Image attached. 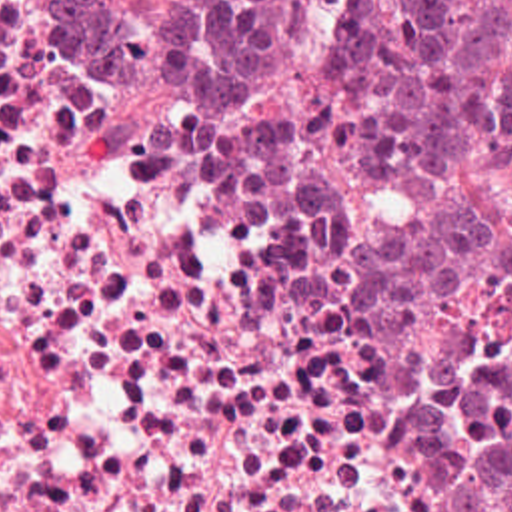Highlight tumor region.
<instances>
[{
	"mask_svg": "<svg viewBox=\"0 0 512 512\" xmlns=\"http://www.w3.org/2000/svg\"><path fill=\"white\" fill-rule=\"evenodd\" d=\"M143 85L199 81L305 125L329 277L359 317L481 293L509 355L455 377L419 446L453 512H512V0H69Z\"/></svg>",
	"mask_w": 512,
	"mask_h": 512,
	"instance_id": "tumor-region-1",
	"label": "tumor region"
}]
</instances>
